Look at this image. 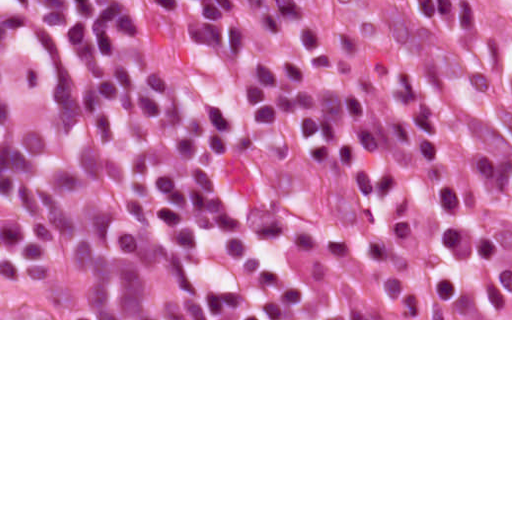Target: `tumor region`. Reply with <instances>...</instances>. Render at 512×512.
<instances>
[{
	"label": "tumor region",
	"instance_id": "obj_1",
	"mask_svg": "<svg viewBox=\"0 0 512 512\" xmlns=\"http://www.w3.org/2000/svg\"><path fill=\"white\" fill-rule=\"evenodd\" d=\"M460 215L380 261H304L183 210L0 38V318H210L214 283L172 254L299 303L441 310L512 303V159L463 124Z\"/></svg>",
	"mask_w": 512,
	"mask_h": 512
}]
</instances>
